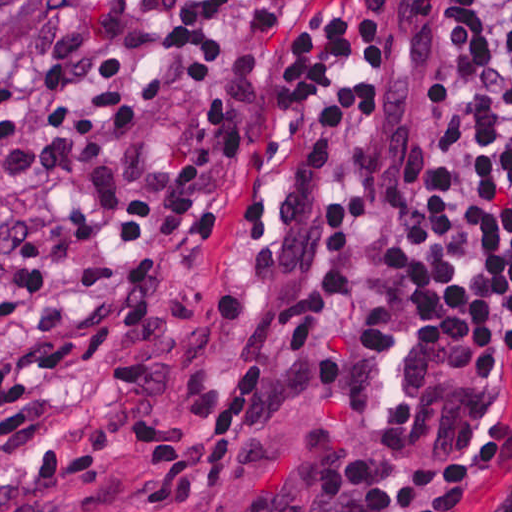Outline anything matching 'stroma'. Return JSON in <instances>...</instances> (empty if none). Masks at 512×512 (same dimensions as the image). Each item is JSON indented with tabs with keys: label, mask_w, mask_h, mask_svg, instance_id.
<instances>
[{
	"label": "stroma",
	"mask_w": 512,
	"mask_h": 512,
	"mask_svg": "<svg viewBox=\"0 0 512 512\" xmlns=\"http://www.w3.org/2000/svg\"><path fill=\"white\" fill-rule=\"evenodd\" d=\"M447 1L0 0V512H349L338 416L256 417L332 195L413 213ZM498 347L380 319L365 434L512 496Z\"/></svg>",
	"instance_id": "obj_1"
}]
</instances>
